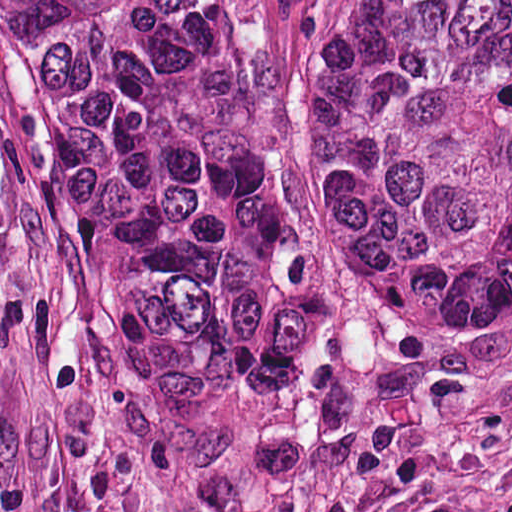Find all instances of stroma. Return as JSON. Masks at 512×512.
Returning a JSON list of instances; mask_svg holds the SVG:
<instances>
[{
  "label": "stroma",
  "mask_w": 512,
  "mask_h": 512,
  "mask_svg": "<svg viewBox=\"0 0 512 512\" xmlns=\"http://www.w3.org/2000/svg\"><path fill=\"white\" fill-rule=\"evenodd\" d=\"M296 96L298 0H278ZM0 512H512V310H400L326 250L304 401L241 451L108 397L49 138L0 7Z\"/></svg>",
  "instance_id": "1"
}]
</instances>
